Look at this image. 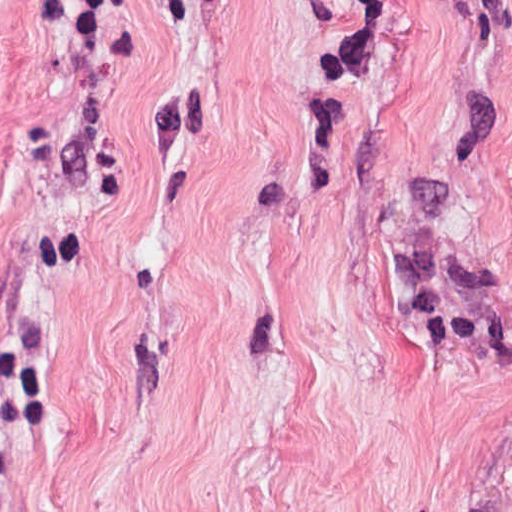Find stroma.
<instances>
[{
  "label": "stroma",
  "instance_id": "stroma-1",
  "mask_svg": "<svg viewBox=\"0 0 512 512\" xmlns=\"http://www.w3.org/2000/svg\"><path fill=\"white\" fill-rule=\"evenodd\" d=\"M0 512H512V0H0Z\"/></svg>",
  "mask_w": 512,
  "mask_h": 512
}]
</instances>
